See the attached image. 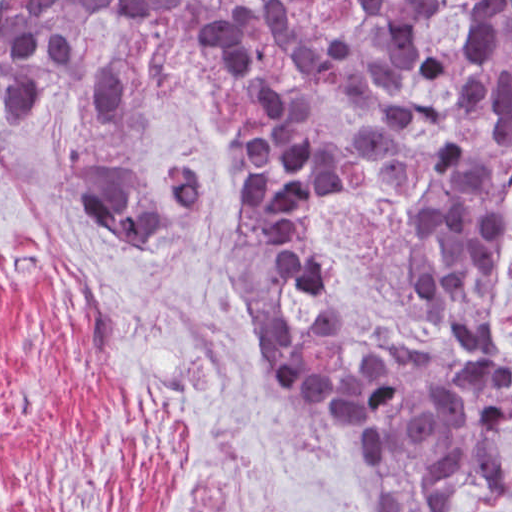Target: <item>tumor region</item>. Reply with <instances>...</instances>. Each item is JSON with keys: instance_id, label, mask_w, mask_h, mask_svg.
Listing matches in <instances>:
<instances>
[{"instance_id": "e687c5a6", "label": "tumor region", "mask_w": 512, "mask_h": 512, "mask_svg": "<svg viewBox=\"0 0 512 512\" xmlns=\"http://www.w3.org/2000/svg\"><path fill=\"white\" fill-rule=\"evenodd\" d=\"M211 0L0 2V107L24 126L72 69L108 16L160 44L158 60L126 56L94 76L85 115L123 120L183 77L218 119V161L237 188L239 220L226 251L239 302L290 400L342 453L352 512H451L466 496L497 494L512 465V364L498 346V300L510 263L512 147L481 154L427 198L421 240L437 268L439 334H320L298 338L295 303L249 202L274 178L284 126L212 81L193 51ZM512 76V0L502 47L485 65ZM84 213L138 261H158V229L207 202L200 174L173 170L163 193L112 167L68 174Z\"/></svg>"}]
</instances>
